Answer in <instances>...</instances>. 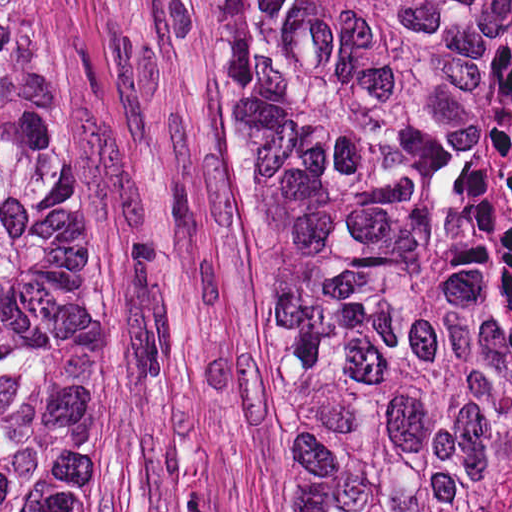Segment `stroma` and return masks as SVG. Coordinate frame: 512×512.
<instances>
[{
	"label": "stroma",
	"mask_w": 512,
	"mask_h": 512,
	"mask_svg": "<svg viewBox=\"0 0 512 512\" xmlns=\"http://www.w3.org/2000/svg\"><path fill=\"white\" fill-rule=\"evenodd\" d=\"M90 138V418L119 512H298L253 175L193 0H25Z\"/></svg>",
	"instance_id": "35a3bbf8"
}]
</instances>
